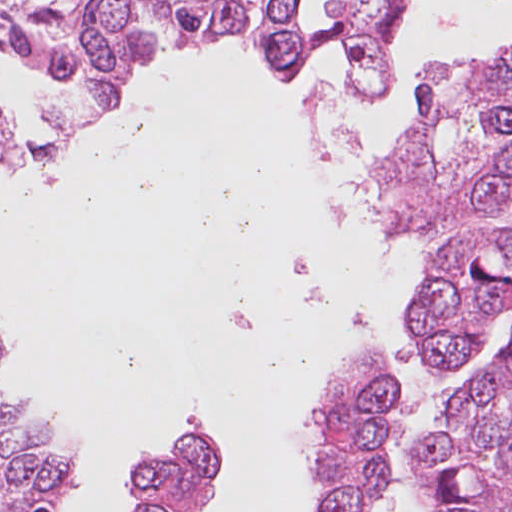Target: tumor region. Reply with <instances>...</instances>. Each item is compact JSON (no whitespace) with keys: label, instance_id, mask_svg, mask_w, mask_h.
I'll return each mask as SVG.
<instances>
[{"label":"tumor region","instance_id":"tumor-region-1","mask_svg":"<svg viewBox=\"0 0 512 512\" xmlns=\"http://www.w3.org/2000/svg\"><path fill=\"white\" fill-rule=\"evenodd\" d=\"M391 0H343L359 21L360 77L384 75ZM266 48L288 75L338 37L312 27L300 0H261ZM234 0H0V58L45 63L81 83L71 122L94 130L120 113L138 68L235 38ZM24 159V137L0 106V165ZM385 205L427 233L512 205V55L449 71L422 87L413 146L385 177Z\"/></svg>","mask_w":512,"mask_h":512}]
</instances>
